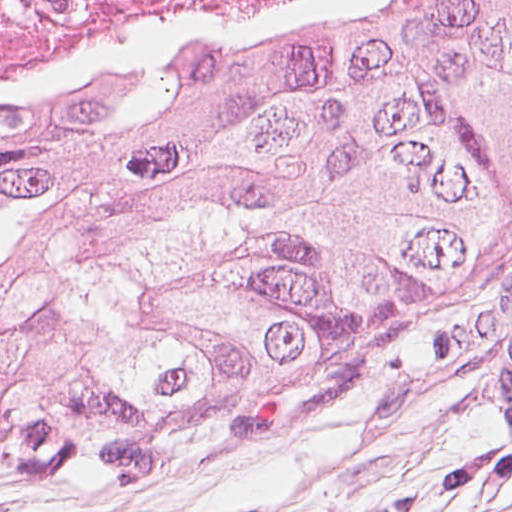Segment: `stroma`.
<instances>
[{"instance_id": "stroma-1", "label": "stroma", "mask_w": 512, "mask_h": 512, "mask_svg": "<svg viewBox=\"0 0 512 512\" xmlns=\"http://www.w3.org/2000/svg\"><path fill=\"white\" fill-rule=\"evenodd\" d=\"M512 317V253L437 328L289 441L512 487L499 346Z\"/></svg>"}]
</instances>
